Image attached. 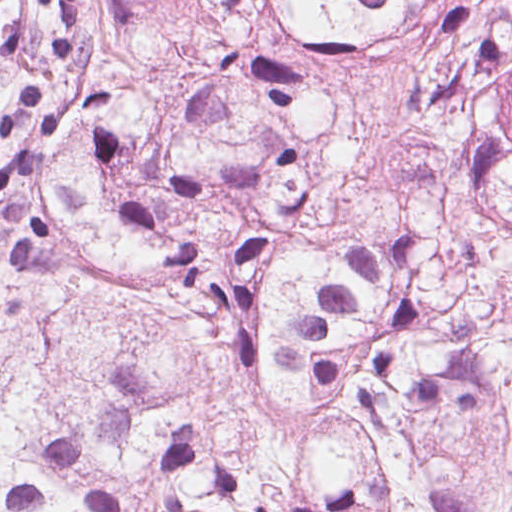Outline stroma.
I'll list each match as a JSON object with an SVG mask.
<instances>
[{"label": "stroma", "instance_id": "obj_1", "mask_svg": "<svg viewBox=\"0 0 512 512\" xmlns=\"http://www.w3.org/2000/svg\"><path fill=\"white\" fill-rule=\"evenodd\" d=\"M7 293L33 296L28 266L0 221V296Z\"/></svg>", "mask_w": 512, "mask_h": 512}]
</instances>
